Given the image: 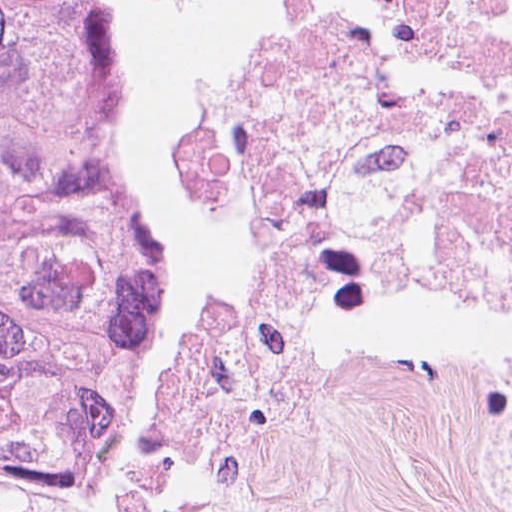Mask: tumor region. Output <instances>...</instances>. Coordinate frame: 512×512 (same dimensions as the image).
Returning a JSON list of instances; mask_svg holds the SVG:
<instances>
[{
  "mask_svg": "<svg viewBox=\"0 0 512 512\" xmlns=\"http://www.w3.org/2000/svg\"><path fill=\"white\" fill-rule=\"evenodd\" d=\"M189 311L77 0H0V454L66 461L183 409Z\"/></svg>",
  "mask_w": 512,
  "mask_h": 512,
  "instance_id": "obj_1",
  "label": "tumor region"
}]
</instances>
